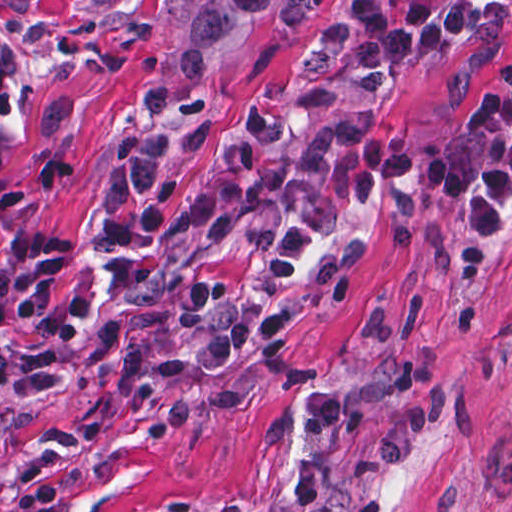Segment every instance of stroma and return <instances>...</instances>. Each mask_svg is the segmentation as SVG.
<instances>
[{
	"mask_svg": "<svg viewBox=\"0 0 512 512\" xmlns=\"http://www.w3.org/2000/svg\"><path fill=\"white\" fill-rule=\"evenodd\" d=\"M349 0H275L202 82L164 72L165 0H0L18 114L0 153V266L16 235L73 243L53 295L99 360L65 349L48 391L0 397V512H512V240L477 248L468 212L407 198L325 234L266 346L196 374L181 268L266 267L269 239L180 231L197 175L255 99L292 103ZM418 3L423 0H406ZM512 0L480 29L355 91L305 145L467 124L502 83ZM171 181L165 228L109 248L100 223Z\"/></svg>",
	"mask_w": 512,
	"mask_h": 512,
	"instance_id": "obj_1",
	"label": "stroma"
}]
</instances>
